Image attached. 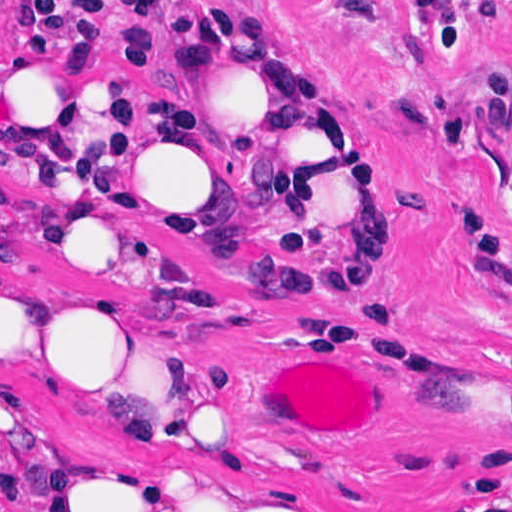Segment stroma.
<instances>
[{
    "label": "stroma",
    "mask_w": 512,
    "mask_h": 512,
    "mask_svg": "<svg viewBox=\"0 0 512 512\" xmlns=\"http://www.w3.org/2000/svg\"><path fill=\"white\" fill-rule=\"evenodd\" d=\"M19 1L0 0V512H41L69 452L138 445L88 425L46 365L52 296L81 288L172 316L194 369L245 393L255 432L181 455L301 512H512V0H29L141 77L183 130L190 25L224 8L285 24L324 72L376 206L387 304L308 283L291 187L219 181L188 135L213 221L202 258L102 282L83 258L17 246L1 206V22ZM324 356L377 405L365 441L265 427L275 364Z\"/></svg>",
    "instance_id": "stroma-1"
}]
</instances>
